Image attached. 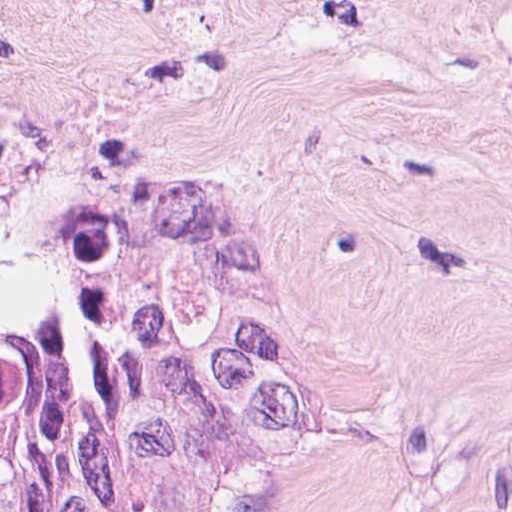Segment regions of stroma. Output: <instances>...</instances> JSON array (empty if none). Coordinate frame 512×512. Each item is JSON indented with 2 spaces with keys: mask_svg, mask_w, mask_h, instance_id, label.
Here are the masks:
<instances>
[{
  "mask_svg": "<svg viewBox=\"0 0 512 512\" xmlns=\"http://www.w3.org/2000/svg\"><path fill=\"white\" fill-rule=\"evenodd\" d=\"M230 317L282 512H512V0H33L0 317Z\"/></svg>",
  "mask_w": 512,
  "mask_h": 512,
  "instance_id": "obj_1",
  "label": "stroma"
}]
</instances>
